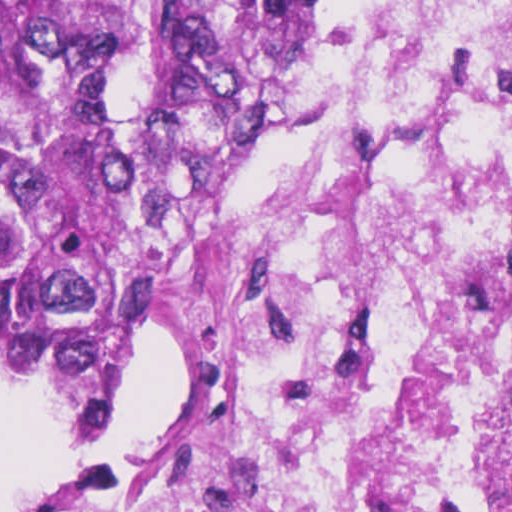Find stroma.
Wrapping results in <instances>:
<instances>
[{
	"mask_svg": "<svg viewBox=\"0 0 512 512\" xmlns=\"http://www.w3.org/2000/svg\"><path fill=\"white\" fill-rule=\"evenodd\" d=\"M341 0H304L299 27L298 42L294 61L288 77L286 91L298 76L301 50L318 31L328 13ZM284 93V94H285ZM279 146V114L275 127L260 159L255 175L273 164ZM254 175V176H255ZM164 253L155 261L146 286V332L134 362L130 376L115 403L104 427L120 421L136 405V381L142 365L160 338L159 315L156 296L159 288V268ZM169 387H170V346H169ZM103 427V428H104Z\"/></svg>",
	"mask_w": 512,
	"mask_h": 512,
	"instance_id": "obj_1",
	"label": "stroma"
}]
</instances>
